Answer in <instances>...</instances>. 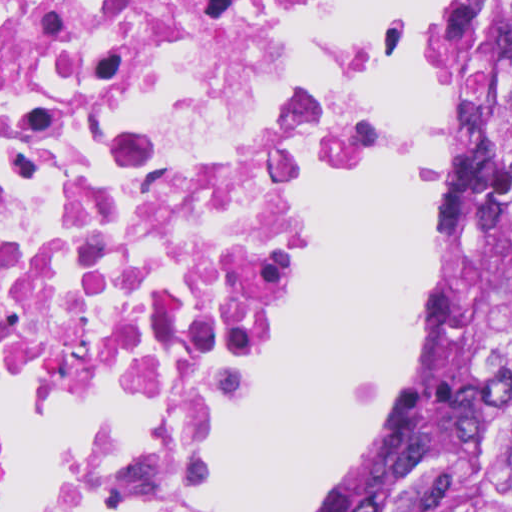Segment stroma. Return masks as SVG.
Here are the masks:
<instances>
[{
    "label": "stroma",
    "instance_id": "obj_1",
    "mask_svg": "<svg viewBox=\"0 0 512 512\" xmlns=\"http://www.w3.org/2000/svg\"><path fill=\"white\" fill-rule=\"evenodd\" d=\"M429 31L438 57V5ZM366 41L374 90L383 109V146L371 175L390 153L393 140L387 105L390 27L378 15L366 27ZM445 327L446 243L438 209L437 156L429 240V313L408 362L379 402L372 421L298 512H374L412 448L430 406ZM233 434L215 454L207 474L205 512H211L214 476Z\"/></svg>",
    "mask_w": 512,
    "mask_h": 512
}]
</instances>
